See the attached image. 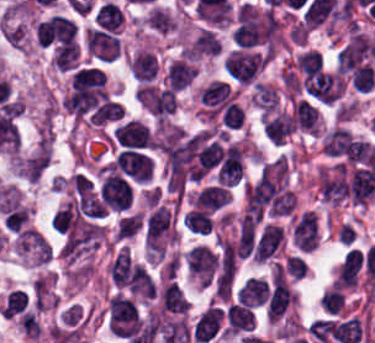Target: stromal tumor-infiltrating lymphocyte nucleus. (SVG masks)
<instances>
[{"mask_svg": "<svg viewBox=\"0 0 375 343\" xmlns=\"http://www.w3.org/2000/svg\"><path fill=\"white\" fill-rule=\"evenodd\" d=\"M269 138L274 143H282L295 128L291 113L279 112L262 123Z\"/></svg>", "mask_w": 375, "mask_h": 343, "instance_id": "obj_14", "label": "stromal tumor-infiltrating lymphocyte nucleus"}, {"mask_svg": "<svg viewBox=\"0 0 375 343\" xmlns=\"http://www.w3.org/2000/svg\"><path fill=\"white\" fill-rule=\"evenodd\" d=\"M325 152L343 164H375L374 143L342 126L327 132Z\"/></svg>", "mask_w": 375, "mask_h": 343, "instance_id": "obj_1", "label": "stromal tumor-infiltrating lymphocyte nucleus"}, {"mask_svg": "<svg viewBox=\"0 0 375 343\" xmlns=\"http://www.w3.org/2000/svg\"><path fill=\"white\" fill-rule=\"evenodd\" d=\"M195 75L189 63L177 59L167 69L165 77L172 86L180 90L190 84Z\"/></svg>", "mask_w": 375, "mask_h": 343, "instance_id": "obj_20", "label": "stromal tumor-infiltrating lymphocyte nucleus"}, {"mask_svg": "<svg viewBox=\"0 0 375 343\" xmlns=\"http://www.w3.org/2000/svg\"><path fill=\"white\" fill-rule=\"evenodd\" d=\"M282 239L279 226L265 225L251 252L252 260H266L276 250Z\"/></svg>", "mask_w": 375, "mask_h": 343, "instance_id": "obj_13", "label": "stromal tumor-infiltrating lymphocyte nucleus"}, {"mask_svg": "<svg viewBox=\"0 0 375 343\" xmlns=\"http://www.w3.org/2000/svg\"><path fill=\"white\" fill-rule=\"evenodd\" d=\"M343 293L336 287L328 288L322 291L320 295V302L323 308L330 312H337L342 304Z\"/></svg>", "mask_w": 375, "mask_h": 343, "instance_id": "obj_32", "label": "stromal tumor-infiltrating lymphocyte nucleus"}, {"mask_svg": "<svg viewBox=\"0 0 375 343\" xmlns=\"http://www.w3.org/2000/svg\"><path fill=\"white\" fill-rule=\"evenodd\" d=\"M268 283L262 276H248L237 289V297L244 302H264Z\"/></svg>", "mask_w": 375, "mask_h": 343, "instance_id": "obj_17", "label": "stromal tumor-infiltrating lymphocyte nucleus"}, {"mask_svg": "<svg viewBox=\"0 0 375 343\" xmlns=\"http://www.w3.org/2000/svg\"><path fill=\"white\" fill-rule=\"evenodd\" d=\"M307 92L320 100H333L342 90V80L336 73L319 71L304 80Z\"/></svg>", "mask_w": 375, "mask_h": 343, "instance_id": "obj_9", "label": "stromal tumor-infiltrating lymphocyte nucleus"}, {"mask_svg": "<svg viewBox=\"0 0 375 343\" xmlns=\"http://www.w3.org/2000/svg\"><path fill=\"white\" fill-rule=\"evenodd\" d=\"M322 60L321 53L315 49H307L296 59L297 64L304 75L312 76Z\"/></svg>", "mask_w": 375, "mask_h": 343, "instance_id": "obj_30", "label": "stromal tumor-infiltrating lymphocyte nucleus"}, {"mask_svg": "<svg viewBox=\"0 0 375 343\" xmlns=\"http://www.w3.org/2000/svg\"><path fill=\"white\" fill-rule=\"evenodd\" d=\"M85 45L98 59L111 60L118 49V40L108 31L95 27L85 30Z\"/></svg>", "mask_w": 375, "mask_h": 343, "instance_id": "obj_12", "label": "stromal tumor-infiltrating lymphocyte nucleus"}, {"mask_svg": "<svg viewBox=\"0 0 375 343\" xmlns=\"http://www.w3.org/2000/svg\"><path fill=\"white\" fill-rule=\"evenodd\" d=\"M28 210L21 203L9 201L1 208V223L8 232H18L25 227Z\"/></svg>", "mask_w": 375, "mask_h": 343, "instance_id": "obj_16", "label": "stromal tumor-infiltrating lymphocyte nucleus"}, {"mask_svg": "<svg viewBox=\"0 0 375 343\" xmlns=\"http://www.w3.org/2000/svg\"><path fill=\"white\" fill-rule=\"evenodd\" d=\"M278 94L270 85L256 81L253 102L265 111H269L273 106Z\"/></svg>", "mask_w": 375, "mask_h": 343, "instance_id": "obj_28", "label": "stromal tumor-infiltrating lymphocyte nucleus"}, {"mask_svg": "<svg viewBox=\"0 0 375 343\" xmlns=\"http://www.w3.org/2000/svg\"><path fill=\"white\" fill-rule=\"evenodd\" d=\"M123 113L122 105L117 100L104 99L95 106L88 119L90 122H106L120 118Z\"/></svg>", "mask_w": 375, "mask_h": 343, "instance_id": "obj_24", "label": "stromal tumor-infiltrating lymphocyte nucleus"}, {"mask_svg": "<svg viewBox=\"0 0 375 343\" xmlns=\"http://www.w3.org/2000/svg\"><path fill=\"white\" fill-rule=\"evenodd\" d=\"M317 190L320 196L326 202L339 203L340 198L331 180V177L327 172L321 174L319 181L317 183Z\"/></svg>", "mask_w": 375, "mask_h": 343, "instance_id": "obj_31", "label": "stromal tumor-infiltrating lymphocyte nucleus"}, {"mask_svg": "<svg viewBox=\"0 0 375 343\" xmlns=\"http://www.w3.org/2000/svg\"><path fill=\"white\" fill-rule=\"evenodd\" d=\"M227 190L218 184L204 186L196 195L194 204L204 208H217L230 198Z\"/></svg>", "mask_w": 375, "mask_h": 343, "instance_id": "obj_18", "label": "stromal tumor-infiltrating lymphocyte nucleus"}, {"mask_svg": "<svg viewBox=\"0 0 375 343\" xmlns=\"http://www.w3.org/2000/svg\"><path fill=\"white\" fill-rule=\"evenodd\" d=\"M173 20L165 10L160 7H153L148 14V27L159 32L166 33L170 31Z\"/></svg>", "mask_w": 375, "mask_h": 343, "instance_id": "obj_29", "label": "stromal tumor-infiltrating lymphocyte nucleus"}, {"mask_svg": "<svg viewBox=\"0 0 375 343\" xmlns=\"http://www.w3.org/2000/svg\"><path fill=\"white\" fill-rule=\"evenodd\" d=\"M94 18L103 28L113 32L121 22L122 11L119 6L107 0L96 10Z\"/></svg>", "mask_w": 375, "mask_h": 343, "instance_id": "obj_23", "label": "stromal tumor-infiltrating lymphocyte nucleus"}, {"mask_svg": "<svg viewBox=\"0 0 375 343\" xmlns=\"http://www.w3.org/2000/svg\"><path fill=\"white\" fill-rule=\"evenodd\" d=\"M78 59V44L63 42L56 50L52 61L58 68L68 69L75 65Z\"/></svg>", "mask_w": 375, "mask_h": 343, "instance_id": "obj_25", "label": "stromal tumor-infiltrating lymphocyte nucleus"}, {"mask_svg": "<svg viewBox=\"0 0 375 343\" xmlns=\"http://www.w3.org/2000/svg\"><path fill=\"white\" fill-rule=\"evenodd\" d=\"M291 236L295 247L312 250L318 242L317 215L307 210L299 213L291 227Z\"/></svg>", "mask_w": 375, "mask_h": 343, "instance_id": "obj_8", "label": "stromal tumor-infiltrating lymphocyte nucleus"}, {"mask_svg": "<svg viewBox=\"0 0 375 343\" xmlns=\"http://www.w3.org/2000/svg\"><path fill=\"white\" fill-rule=\"evenodd\" d=\"M26 303L27 299L24 291L17 287L7 293L0 309L4 314L11 316L21 311Z\"/></svg>", "mask_w": 375, "mask_h": 343, "instance_id": "obj_27", "label": "stromal tumor-infiltrating lymphocyte nucleus"}, {"mask_svg": "<svg viewBox=\"0 0 375 343\" xmlns=\"http://www.w3.org/2000/svg\"><path fill=\"white\" fill-rule=\"evenodd\" d=\"M254 305L239 298L225 300L221 307V329L225 334H247L253 327Z\"/></svg>", "mask_w": 375, "mask_h": 343, "instance_id": "obj_3", "label": "stromal tumor-infiltrating lymphocyte nucleus"}, {"mask_svg": "<svg viewBox=\"0 0 375 343\" xmlns=\"http://www.w3.org/2000/svg\"><path fill=\"white\" fill-rule=\"evenodd\" d=\"M130 69L133 77L148 81L157 73V58L150 51L137 49L133 53Z\"/></svg>", "mask_w": 375, "mask_h": 343, "instance_id": "obj_15", "label": "stromal tumor-infiltrating lymphocyte nucleus"}, {"mask_svg": "<svg viewBox=\"0 0 375 343\" xmlns=\"http://www.w3.org/2000/svg\"><path fill=\"white\" fill-rule=\"evenodd\" d=\"M186 257L188 269L203 282H210L216 267L212 249L204 243H196Z\"/></svg>", "mask_w": 375, "mask_h": 343, "instance_id": "obj_11", "label": "stromal tumor-infiltrating lymphocyte nucleus"}, {"mask_svg": "<svg viewBox=\"0 0 375 343\" xmlns=\"http://www.w3.org/2000/svg\"><path fill=\"white\" fill-rule=\"evenodd\" d=\"M295 124L309 131L317 133L318 112L306 99L293 102Z\"/></svg>", "mask_w": 375, "mask_h": 343, "instance_id": "obj_19", "label": "stromal tumor-infiltrating lymphocyte nucleus"}, {"mask_svg": "<svg viewBox=\"0 0 375 343\" xmlns=\"http://www.w3.org/2000/svg\"><path fill=\"white\" fill-rule=\"evenodd\" d=\"M186 50L189 55L194 56L217 53V37L210 30L203 27Z\"/></svg>", "mask_w": 375, "mask_h": 343, "instance_id": "obj_21", "label": "stromal tumor-infiltrating lymphocyte nucleus"}, {"mask_svg": "<svg viewBox=\"0 0 375 343\" xmlns=\"http://www.w3.org/2000/svg\"><path fill=\"white\" fill-rule=\"evenodd\" d=\"M70 181L76 192H78L80 195H88L91 187V182L86 175L78 171L70 178Z\"/></svg>", "mask_w": 375, "mask_h": 343, "instance_id": "obj_34", "label": "stromal tumor-infiltrating lymphocyte nucleus"}, {"mask_svg": "<svg viewBox=\"0 0 375 343\" xmlns=\"http://www.w3.org/2000/svg\"><path fill=\"white\" fill-rule=\"evenodd\" d=\"M115 163L121 171L138 181H147L153 166L148 155L131 148L119 150Z\"/></svg>", "mask_w": 375, "mask_h": 343, "instance_id": "obj_6", "label": "stromal tumor-infiltrating lymphocyte nucleus"}, {"mask_svg": "<svg viewBox=\"0 0 375 343\" xmlns=\"http://www.w3.org/2000/svg\"><path fill=\"white\" fill-rule=\"evenodd\" d=\"M109 316L114 333H137L138 310L135 303L127 297L115 294L109 300Z\"/></svg>", "mask_w": 375, "mask_h": 343, "instance_id": "obj_4", "label": "stromal tumor-infiltrating lymphocyte nucleus"}, {"mask_svg": "<svg viewBox=\"0 0 375 343\" xmlns=\"http://www.w3.org/2000/svg\"><path fill=\"white\" fill-rule=\"evenodd\" d=\"M228 87L224 81L211 80L199 93V100L204 103H223L227 97Z\"/></svg>", "mask_w": 375, "mask_h": 343, "instance_id": "obj_26", "label": "stromal tumor-infiltrating lymphocyte nucleus"}, {"mask_svg": "<svg viewBox=\"0 0 375 343\" xmlns=\"http://www.w3.org/2000/svg\"><path fill=\"white\" fill-rule=\"evenodd\" d=\"M243 117L242 107L234 102H227L223 112L222 120L226 127H235Z\"/></svg>", "mask_w": 375, "mask_h": 343, "instance_id": "obj_33", "label": "stromal tumor-infiltrating lymphocyte nucleus"}, {"mask_svg": "<svg viewBox=\"0 0 375 343\" xmlns=\"http://www.w3.org/2000/svg\"><path fill=\"white\" fill-rule=\"evenodd\" d=\"M99 192L103 205L114 209H125L132 196L127 180L106 170L103 173Z\"/></svg>", "mask_w": 375, "mask_h": 343, "instance_id": "obj_5", "label": "stromal tumor-infiltrating lymphocyte nucleus"}, {"mask_svg": "<svg viewBox=\"0 0 375 343\" xmlns=\"http://www.w3.org/2000/svg\"><path fill=\"white\" fill-rule=\"evenodd\" d=\"M196 343H207L221 334V305L210 303L193 322Z\"/></svg>", "mask_w": 375, "mask_h": 343, "instance_id": "obj_7", "label": "stromal tumor-infiltrating lymphocyte nucleus"}, {"mask_svg": "<svg viewBox=\"0 0 375 343\" xmlns=\"http://www.w3.org/2000/svg\"><path fill=\"white\" fill-rule=\"evenodd\" d=\"M265 57L258 49L235 47L222 60L231 81L238 85H250L261 73Z\"/></svg>", "mask_w": 375, "mask_h": 343, "instance_id": "obj_2", "label": "stromal tumor-infiltrating lymphocyte nucleus"}, {"mask_svg": "<svg viewBox=\"0 0 375 343\" xmlns=\"http://www.w3.org/2000/svg\"><path fill=\"white\" fill-rule=\"evenodd\" d=\"M141 230V220L137 212L125 211L114 224L115 239H128Z\"/></svg>", "mask_w": 375, "mask_h": 343, "instance_id": "obj_22", "label": "stromal tumor-infiltrating lymphocyte nucleus"}, {"mask_svg": "<svg viewBox=\"0 0 375 343\" xmlns=\"http://www.w3.org/2000/svg\"><path fill=\"white\" fill-rule=\"evenodd\" d=\"M236 268V252L232 243L217 237L216 290H224Z\"/></svg>", "mask_w": 375, "mask_h": 343, "instance_id": "obj_10", "label": "stromal tumor-infiltrating lymphocyte nucleus"}]
</instances>
